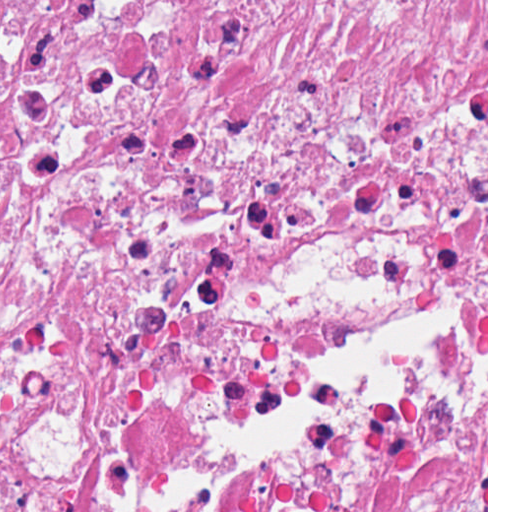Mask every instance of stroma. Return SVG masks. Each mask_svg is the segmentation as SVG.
<instances>
[{
  "instance_id": "obj_1",
  "label": "stroma",
  "mask_w": 512,
  "mask_h": 512,
  "mask_svg": "<svg viewBox=\"0 0 512 512\" xmlns=\"http://www.w3.org/2000/svg\"><path fill=\"white\" fill-rule=\"evenodd\" d=\"M486 395L488 512V0H486V307L438 309V407Z\"/></svg>"
}]
</instances>
